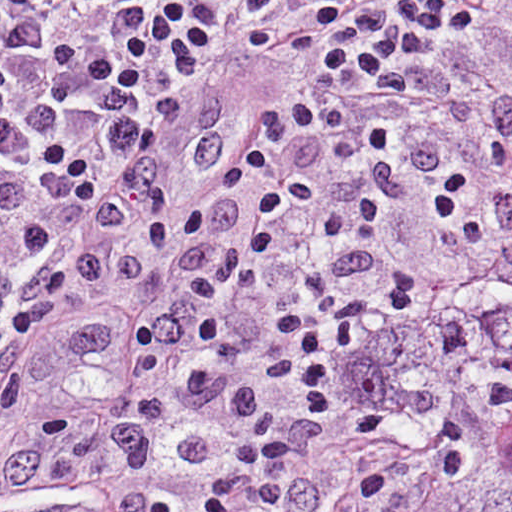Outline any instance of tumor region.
<instances>
[{
    "label": "tumor region",
    "instance_id": "1",
    "mask_svg": "<svg viewBox=\"0 0 512 512\" xmlns=\"http://www.w3.org/2000/svg\"><path fill=\"white\" fill-rule=\"evenodd\" d=\"M371 348L302 487L257 512H512V220Z\"/></svg>",
    "mask_w": 512,
    "mask_h": 512
}]
</instances>
